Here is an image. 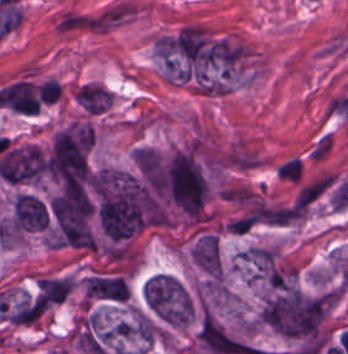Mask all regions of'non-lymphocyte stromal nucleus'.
Wrapping results in <instances>:
<instances>
[{
	"mask_svg": "<svg viewBox=\"0 0 348 354\" xmlns=\"http://www.w3.org/2000/svg\"><path fill=\"white\" fill-rule=\"evenodd\" d=\"M60 32H108L113 30L93 11L66 10L56 26Z\"/></svg>",
	"mask_w": 348,
	"mask_h": 354,
	"instance_id": "obj_1",
	"label": "non-lymphocyte stromal nucleus"
}]
</instances>
